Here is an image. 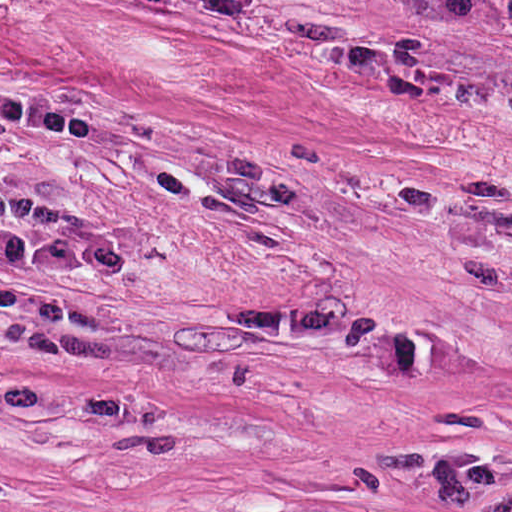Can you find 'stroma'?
Listing matches in <instances>:
<instances>
[{
  "label": "stroma",
  "mask_w": 512,
  "mask_h": 512,
  "mask_svg": "<svg viewBox=\"0 0 512 512\" xmlns=\"http://www.w3.org/2000/svg\"><path fill=\"white\" fill-rule=\"evenodd\" d=\"M0 477L512 512V0H0Z\"/></svg>",
  "instance_id": "obj_1"
}]
</instances>
